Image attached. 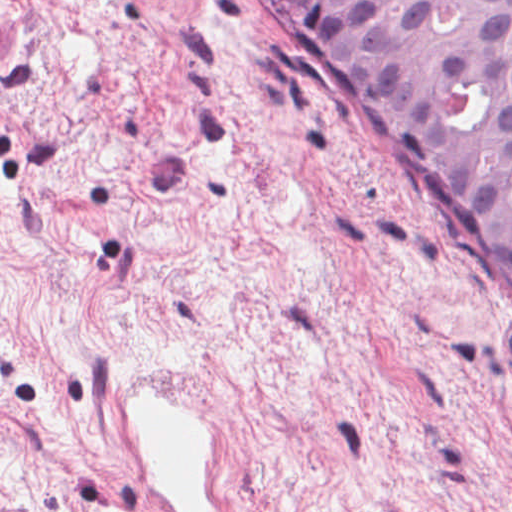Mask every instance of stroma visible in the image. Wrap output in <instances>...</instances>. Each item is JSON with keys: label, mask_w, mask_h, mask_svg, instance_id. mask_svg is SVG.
<instances>
[{"label": "stroma", "mask_w": 512, "mask_h": 512, "mask_svg": "<svg viewBox=\"0 0 512 512\" xmlns=\"http://www.w3.org/2000/svg\"><path fill=\"white\" fill-rule=\"evenodd\" d=\"M0 512H512V327L274 0H0Z\"/></svg>", "instance_id": "obj_1"}]
</instances>
